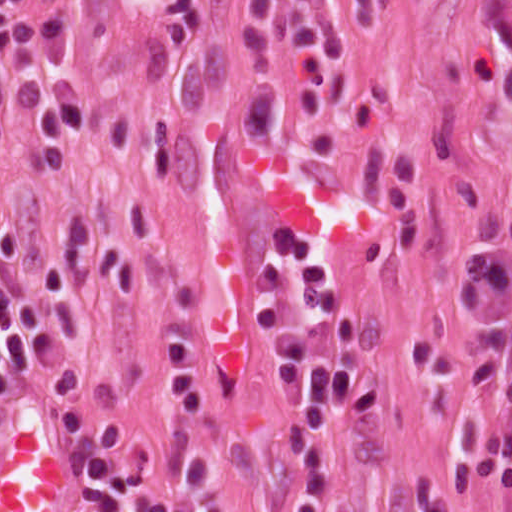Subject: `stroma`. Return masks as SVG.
Returning <instances> with one entry per match:
<instances>
[{
	"mask_svg": "<svg viewBox=\"0 0 512 512\" xmlns=\"http://www.w3.org/2000/svg\"><path fill=\"white\" fill-rule=\"evenodd\" d=\"M329 8L342 57L310 54L304 114L287 73L284 5ZM283 221L323 249L360 320L311 347L381 381L341 414L323 512H417L420 470L448 505L501 512L455 481L440 390L410 361L501 335L479 430L512 339V0H0V232L10 277L55 255L88 338L0 400V428L39 396L126 419L152 451L151 493L188 481L169 370L199 348L204 422L234 512H295L300 424L252 323L258 269ZM478 266L508 276V318L455 320ZM79 512V472H78Z\"/></svg>",
	"mask_w": 512,
	"mask_h": 512,
	"instance_id": "stroma-1",
	"label": "stroma"
}]
</instances>
